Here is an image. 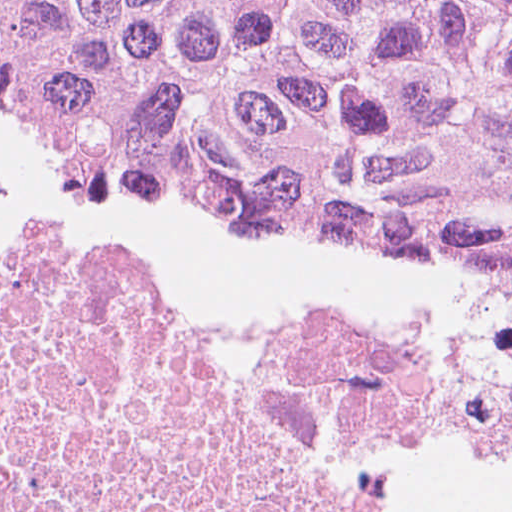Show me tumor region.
<instances>
[{"label":"tumor region","mask_w":512,"mask_h":512,"mask_svg":"<svg viewBox=\"0 0 512 512\" xmlns=\"http://www.w3.org/2000/svg\"><path fill=\"white\" fill-rule=\"evenodd\" d=\"M0 95L270 211L512 251V0H0Z\"/></svg>","instance_id":"1"}]
</instances>
